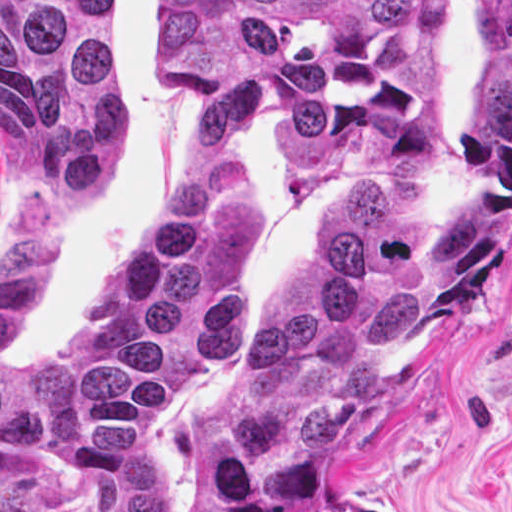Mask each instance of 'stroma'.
Wrapping results in <instances>:
<instances>
[{
  "label": "stroma",
  "instance_id": "stroma-1",
  "mask_svg": "<svg viewBox=\"0 0 512 512\" xmlns=\"http://www.w3.org/2000/svg\"><path fill=\"white\" fill-rule=\"evenodd\" d=\"M483 55V0H451L441 100L431 145L414 157L366 159L320 181L274 144L265 118L243 113L208 133L167 76V0H121L111 77L121 97V154L100 190L50 204L0 147V253L14 243L30 202L53 222V263L11 363L37 367L72 329L86 300L141 247L175 203L205 142L226 149L247 181V327L151 420L149 447L184 512L203 480L200 436L252 362L265 326L341 212L375 179L415 177L460 193L466 102ZM43 512H97L90 477L51 454ZM364 500L376 512H512V239L478 299L425 365L354 422L334 486L302 512Z\"/></svg>",
  "mask_w": 512,
  "mask_h": 512
}]
</instances>
